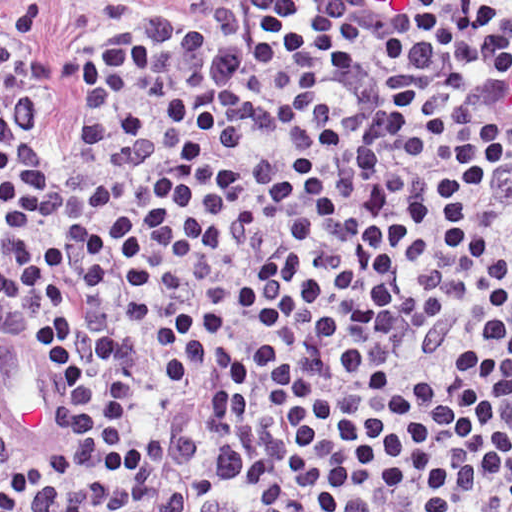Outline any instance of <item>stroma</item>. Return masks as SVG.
Segmentation results:
<instances>
[{
	"mask_svg": "<svg viewBox=\"0 0 512 512\" xmlns=\"http://www.w3.org/2000/svg\"><path fill=\"white\" fill-rule=\"evenodd\" d=\"M293 1L512 0H0V512L1 51L34 90L38 150L62 164L81 150L86 118L81 60L97 40L144 17H172L214 41L228 94L254 100L287 52Z\"/></svg>",
	"mask_w": 512,
	"mask_h": 512,
	"instance_id": "obj_1",
	"label": "stroma"
}]
</instances>
